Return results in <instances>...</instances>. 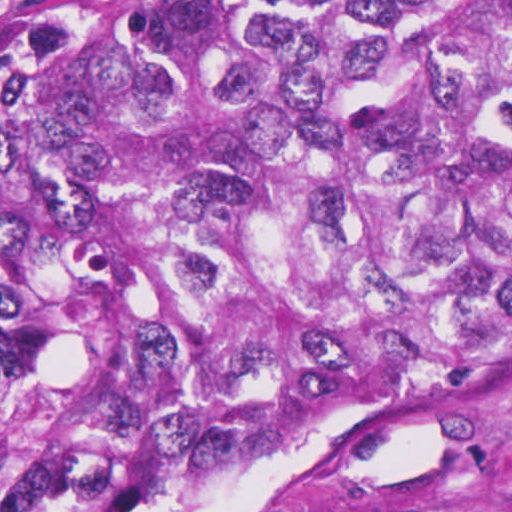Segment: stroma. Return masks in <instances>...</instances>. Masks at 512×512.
<instances>
[{
  "mask_svg": "<svg viewBox=\"0 0 512 512\" xmlns=\"http://www.w3.org/2000/svg\"><path fill=\"white\" fill-rule=\"evenodd\" d=\"M61 1L0 0V35ZM151 512H512V361L404 411L178 474Z\"/></svg>",
  "mask_w": 512,
  "mask_h": 512,
  "instance_id": "1",
  "label": "stroma"
}]
</instances>
